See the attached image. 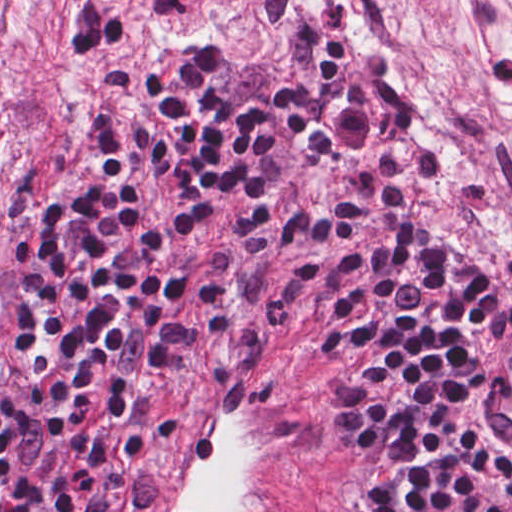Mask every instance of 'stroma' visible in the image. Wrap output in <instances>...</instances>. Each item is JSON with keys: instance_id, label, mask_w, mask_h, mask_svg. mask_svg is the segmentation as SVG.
I'll return each instance as SVG.
<instances>
[{"instance_id": "35a3bbf8", "label": "stroma", "mask_w": 512, "mask_h": 512, "mask_svg": "<svg viewBox=\"0 0 512 512\" xmlns=\"http://www.w3.org/2000/svg\"><path fill=\"white\" fill-rule=\"evenodd\" d=\"M223 39L342 106L413 196L512 271V0H242L208 35H171L138 0H0V280L17 204L75 129L170 58ZM245 343L276 364L334 455L316 364L262 315L208 307L171 395Z\"/></svg>"}]
</instances>
